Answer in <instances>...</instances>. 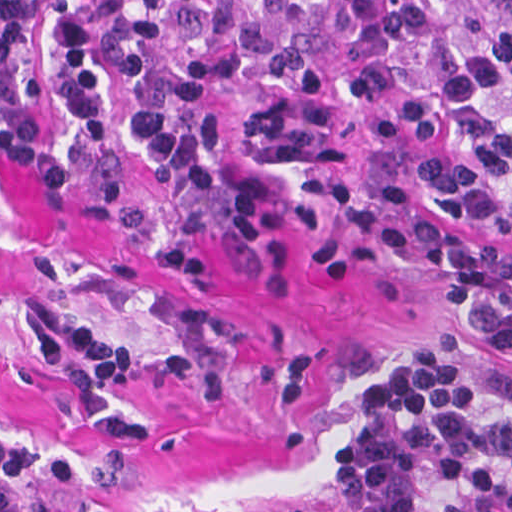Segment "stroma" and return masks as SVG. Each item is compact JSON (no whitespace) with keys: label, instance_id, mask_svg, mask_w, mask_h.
<instances>
[{"label":"stroma","instance_id":"obj_1","mask_svg":"<svg viewBox=\"0 0 512 512\" xmlns=\"http://www.w3.org/2000/svg\"><path fill=\"white\" fill-rule=\"evenodd\" d=\"M443 146L372 139L360 181L407 188L414 215L512 261V235L441 207L418 169ZM443 302L423 257L363 263L311 248L273 274L196 196L114 150L86 103L0 113V434L79 459L68 492L31 485L43 512H348L337 452L377 376L437 330L512 386V349ZM42 322L102 329L139 355L188 356L229 381L219 401L147 376L114 406L144 435L83 429L38 355Z\"/></svg>","mask_w":512,"mask_h":512}]
</instances>
